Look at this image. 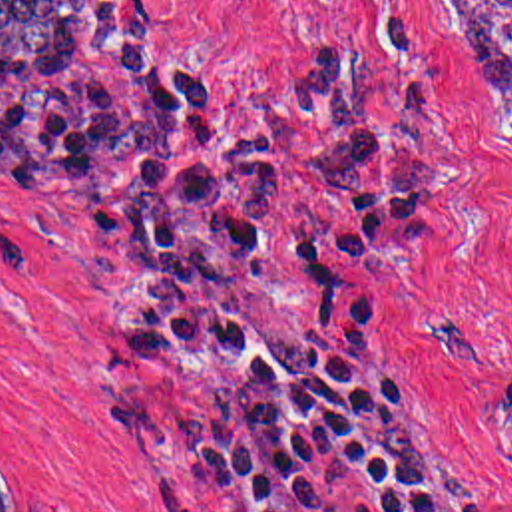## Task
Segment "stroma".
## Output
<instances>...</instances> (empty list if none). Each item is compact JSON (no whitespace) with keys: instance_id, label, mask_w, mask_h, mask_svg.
<instances>
[{"instance_id":"stroma-1","label":"stroma","mask_w":512,"mask_h":512,"mask_svg":"<svg viewBox=\"0 0 512 512\" xmlns=\"http://www.w3.org/2000/svg\"><path fill=\"white\" fill-rule=\"evenodd\" d=\"M127 39L207 67L217 103L286 167L268 256L237 290L256 348L286 374L278 272L304 229L314 169L282 89L300 57L356 73L380 137L442 161L428 225L392 234L396 274L378 304V380L458 512H512V135L448 0H99ZM416 7L436 27L446 81L434 135L390 75L378 7ZM121 161L53 107L0 91V464L45 512H254L266 464L227 487L153 464L105 430L111 406L185 418L229 364L135 372L123 334L143 304L125 240Z\"/></svg>"}]
</instances>
